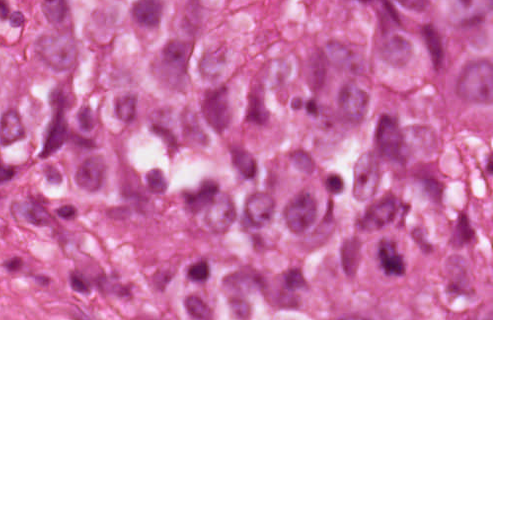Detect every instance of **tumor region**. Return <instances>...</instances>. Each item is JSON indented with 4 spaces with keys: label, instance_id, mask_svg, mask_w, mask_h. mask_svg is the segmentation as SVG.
<instances>
[{
    "label": "tumor region",
    "instance_id": "1",
    "mask_svg": "<svg viewBox=\"0 0 512 512\" xmlns=\"http://www.w3.org/2000/svg\"><path fill=\"white\" fill-rule=\"evenodd\" d=\"M0 319H492L491 0H0Z\"/></svg>",
    "mask_w": 512,
    "mask_h": 512
}]
</instances>
